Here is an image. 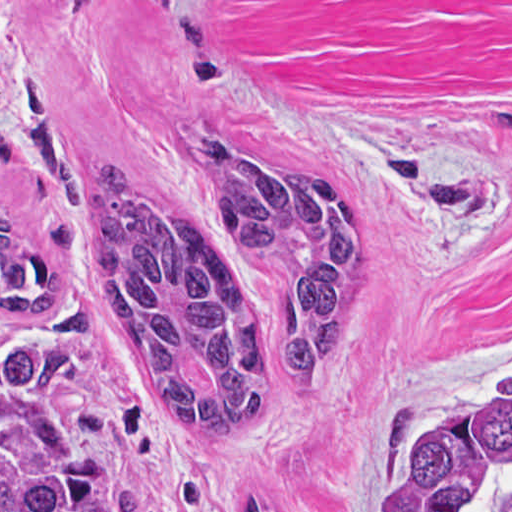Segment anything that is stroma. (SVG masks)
Instances as JSON below:
<instances>
[{
  "label": "stroma",
  "instance_id": "35a3bbf8",
  "mask_svg": "<svg viewBox=\"0 0 512 512\" xmlns=\"http://www.w3.org/2000/svg\"><path fill=\"white\" fill-rule=\"evenodd\" d=\"M41 89L83 169L162 198L209 138L368 200L365 278L317 354L218 441L105 409L108 512H216L259 490L367 512L417 438L512 386V0H0V207L65 270L37 326L88 354L92 205L38 187L13 108Z\"/></svg>",
  "mask_w": 512,
  "mask_h": 512
}]
</instances>
